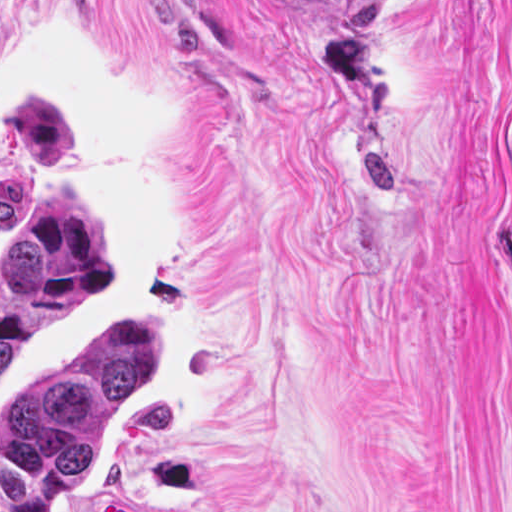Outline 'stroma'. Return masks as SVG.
Listing matches in <instances>:
<instances>
[{
  "instance_id": "35a3bbf8",
  "label": "stroma",
  "mask_w": 512,
  "mask_h": 512,
  "mask_svg": "<svg viewBox=\"0 0 512 512\" xmlns=\"http://www.w3.org/2000/svg\"><path fill=\"white\" fill-rule=\"evenodd\" d=\"M512 0H0V259L71 194L152 383L51 512H512Z\"/></svg>"
}]
</instances>
